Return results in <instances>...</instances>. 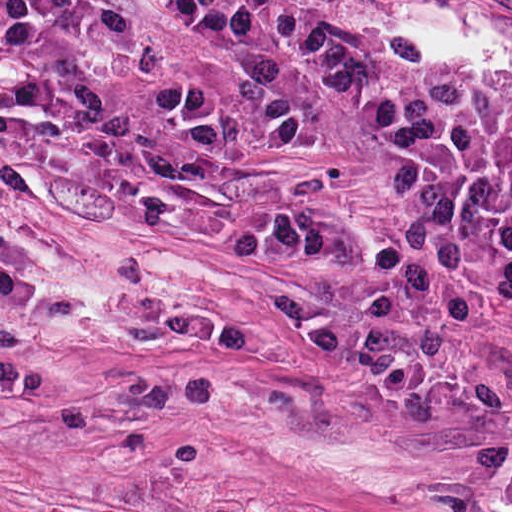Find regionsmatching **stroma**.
<instances>
[{
	"instance_id": "obj_1",
	"label": "stroma",
	"mask_w": 512,
	"mask_h": 512,
	"mask_svg": "<svg viewBox=\"0 0 512 512\" xmlns=\"http://www.w3.org/2000/svg\"><path fill=\"white\" fill-rule=\"evenodd\" d=\"M106 1L156 73L96 100L0 66V512H512V329L485 301L460 330L339 310L374 271L233 260V227L336 216L369 253L405 225L371 82L281 40L215 49L178 0ZM238 1L512 125V0Z\"/></svg>"
}]
</instances>
